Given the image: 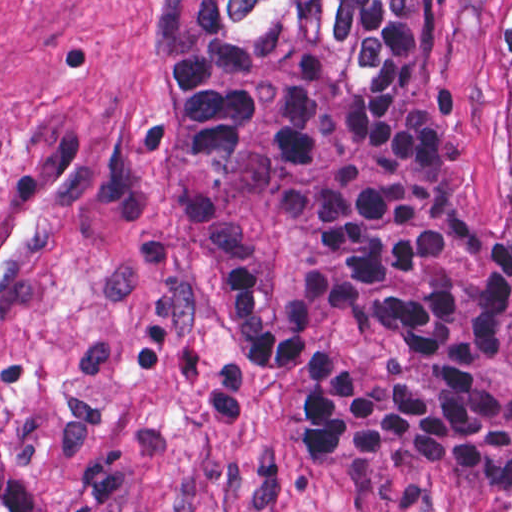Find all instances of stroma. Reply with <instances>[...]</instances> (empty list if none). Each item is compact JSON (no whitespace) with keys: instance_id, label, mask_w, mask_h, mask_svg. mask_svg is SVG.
I'll return each instance as SVG.
<instances>
[{"instance_id":"stroma-1","label":"stroma","mask_w":512,"mask_h":512,"mask_svg":"<svg viewBox=\"0 0 512 512\" xmlns=\"http://www.w3.org/2000/svg\"><path fill=\"white\" fill-rule=\"evenodd\" d=\"M154 0H0V455L51 512H494L443 472L319 476L213 291L149 58ZM436 4V157L512 230L490 0Z\"/></svg>"}]
</instances>
